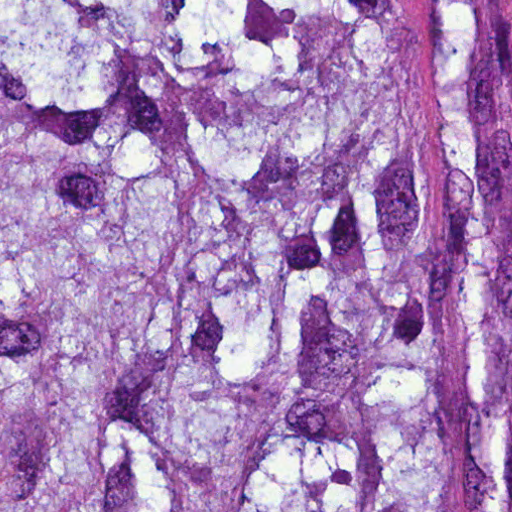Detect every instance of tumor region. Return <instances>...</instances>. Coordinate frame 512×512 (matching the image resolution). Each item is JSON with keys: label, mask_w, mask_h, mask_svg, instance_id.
Returning a JSON list of instances; mask_svg holds the SVG:
<instances>
[{"label": "tumor region", "mask_w": 512, "mask_h": 512, "mask_svg": "<svg viewBox=\"0 0 512 512\" xmlns=\"http://www.w3.org/2000/svg\"><path fill=\"white\" fill-rule=\"evenodd\" d=\"M0 512H512V0H0Z\"/></svg>", "instance_id": "obj_1"}]
</instances>
